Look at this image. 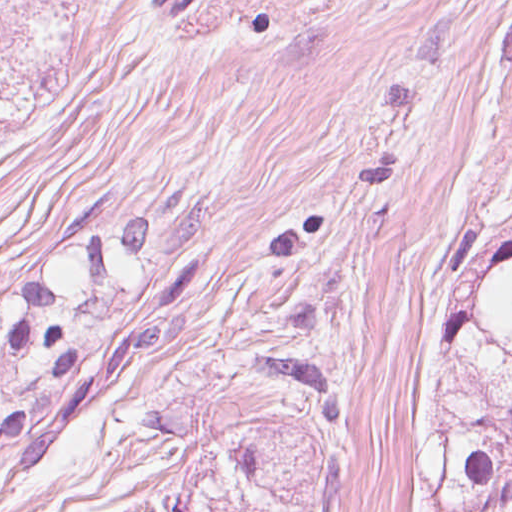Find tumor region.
<instances>
[{
	"label": "tumor region",
	"mask_w": 512,
	"mask_h": 512,
	"mask_svg": "<svg viewBox=\"0 0 512 512\" xmlns=\"http://www.w3.org/2000/svg\"><path fill=\"white\" fill-rule=\"evenodd\" d=\"M208 190L155 217L83 195L49 254L0 273V481L140 363L196 274ZM415 453L431 512L512 500V287L438 263L410 295Z\"/></svg>",
	"instance_id": "1"
}]
</instances>
